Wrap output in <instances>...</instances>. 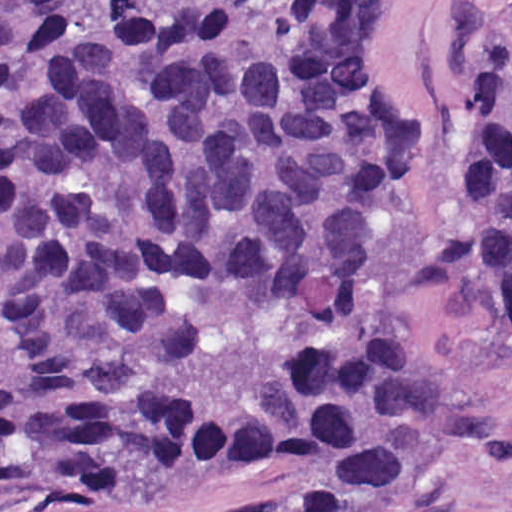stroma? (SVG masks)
<instances>
[{
    "label": "stroma",
    "mask_w": 512,
    "mask_h": 512,
    "mask_svg": "<svg viewBox=\"0 0 512 512\" xmlns=\"http://www.w3.org/2000/svg\"><path fill=\"white\" fill-rule=\"evenodd\" d=\"M387 54L425 145L379 237L366 303L379 336L447 376L468 440H440L350 512H512V316L462 265V203L480 132V70L512 38V0H384ZM0 512H288L276 476L162 472L67 499L0 493Z\"/></svg>",
    "instance_id": "1"
}]
</instances>
